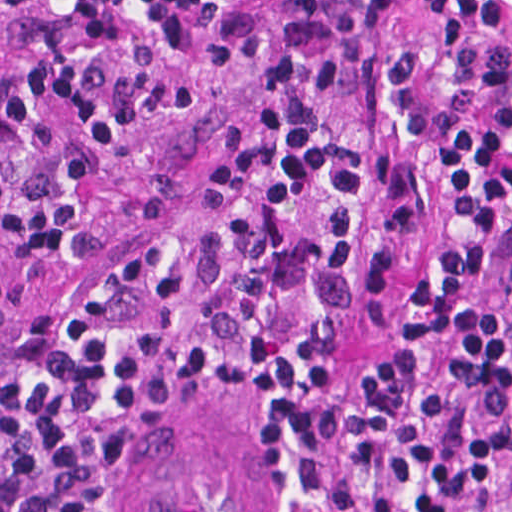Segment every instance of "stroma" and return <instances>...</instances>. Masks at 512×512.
I'll use <instances>...</instances> for the list:
<instances>
[{"label":"stroma","mask_w":512,"mask_h":512,"mask_svg":"<svg viewBox=\"0 0 512 512\" xmlns=\"http://www.w3.org/2000/svg\"><path fill=\"white\" fill-rule=\"evenodd\" d=\"M235 0H0V386L35 316L83 294L132 232L206 180L221 130L261 96L256 59L206 43ZM418 36L416 0H389L318 100L357 180L360 232L391 256L379 307L332 328L336 354L392 353L413 277L404 230L375 220L364 151L388 148L375 101L379 56ZM512 267L479 268L470 298L509 320ZM263 397L247 384L172 399L119 463L116 512H252Z\"/></svg>","instance_id":"1"}]
</instances>
